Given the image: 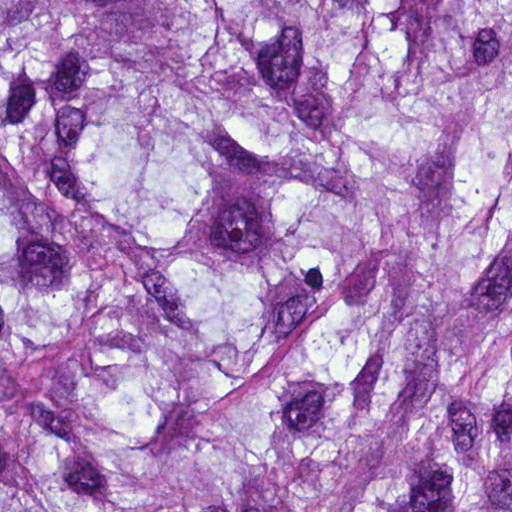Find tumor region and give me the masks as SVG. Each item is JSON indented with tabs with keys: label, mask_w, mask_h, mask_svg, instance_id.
<instances>
[{
	"label": "tumor region",
	"mask_w": 512,
	"mask_h": 512,
	"mask_svg": "<svg viewBox=\"0 0 512 512\" xmlns=\"http://www.w3.org/2000/svg\"><path fill=\"white\" fill-rule=\"evenodd\" d=\"M1 512H512V0H1Z\"/></svg>",
	"instance_id": "tumor-region-1"
}]
</instances>
